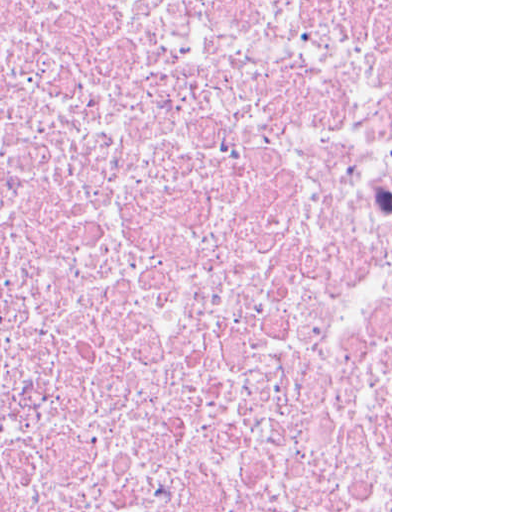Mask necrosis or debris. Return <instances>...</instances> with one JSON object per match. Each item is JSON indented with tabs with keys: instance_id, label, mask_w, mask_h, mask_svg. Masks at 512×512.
<instances>
[{
	"instance_id": "necrosis-or-debris-1",
	"label": "necrosis or debris",
	"mask_w": 512,
	"mask_h": 512,
	"mask_svg": "<svg viewBox=\"0 0 512 512\" xmlns=\"http://www.w3.org/2000/svg\"><path fill=\"white\" fill-rule=\"evenodd\" d=\"M0 512H391V0H0Z\"/></svg>"
}]
</instances>
